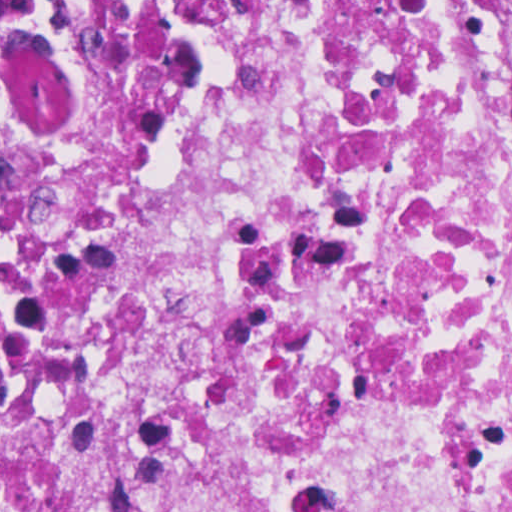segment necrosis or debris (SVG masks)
<instances>
[{
  "instance_id": "4bbe7bcc",
  "label": "necrosis or debris",
  "mask_w": 512,
  "mask_h": 512,
  "mask_svg": "<svg viewBox=\"0 0 512 512\" xmlns=\"http://www.w3.org/2000/svg\"><path fill=\"white\" fill-rule=\"evenodd\" d=\"M0 512H512V0H3Z\"/></svg>"
}]
</instances>
